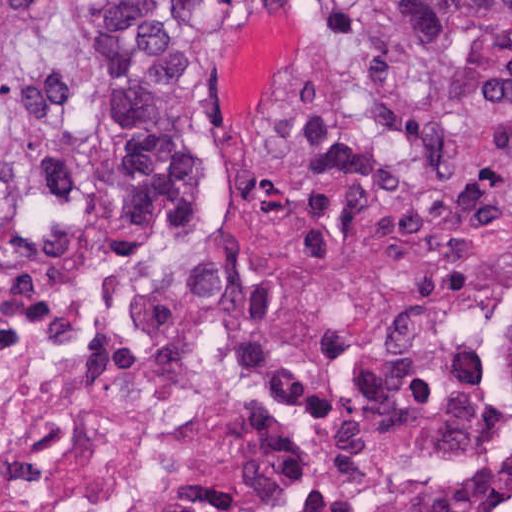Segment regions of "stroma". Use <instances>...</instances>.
<instances>
[{"mask_svg": "<svg viewBox=\"0 0 512 512\" xmlns=\"http://www.w3.org/2000/svg\"><path fill=\"white\" fill-rule=\"evenodd\" d=\"M336 1L216 0L184 67V118L201 171L203 203L229 255L227 289H242L273 265L355 269L425 233L362 232L314 251H275L247 214L250 174L271 107L303 32ZM443 230H512V219H480ZM99 232L127 254L118 240ZM509 388L512 397V359Z\"/></svg>", "mask_w": 512, "mask_h": 512, "instance_id": "stroma-1", "label": "stroma"}]
</instances>
